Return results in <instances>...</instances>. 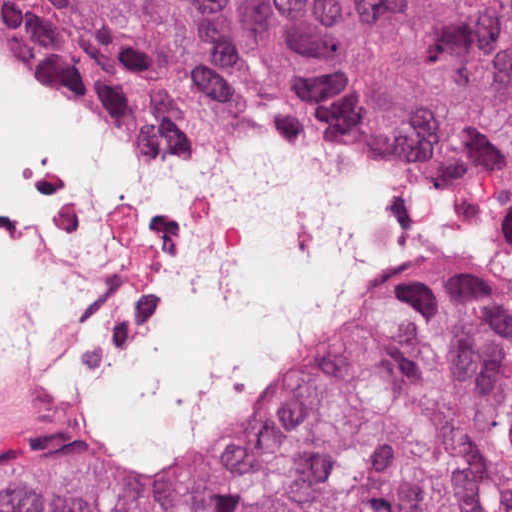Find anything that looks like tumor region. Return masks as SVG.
<instances>
[{
	"label": "tumor region",
	"instance_id": "1",
	"mask_svg": "<svg viewBox=\"0 0 512 512\" xmlns=\"http://www.w3.org/2000/svg\"><path fill=\"white\" fill-rule=\"evenodd\" d=\"M0 36L178 134L349 138L490 194L183 457L0 421V512H512V0H0Z\"/></svg>",
	"mask_w": 512,
	"mask_h": 512
}]
</instances>
